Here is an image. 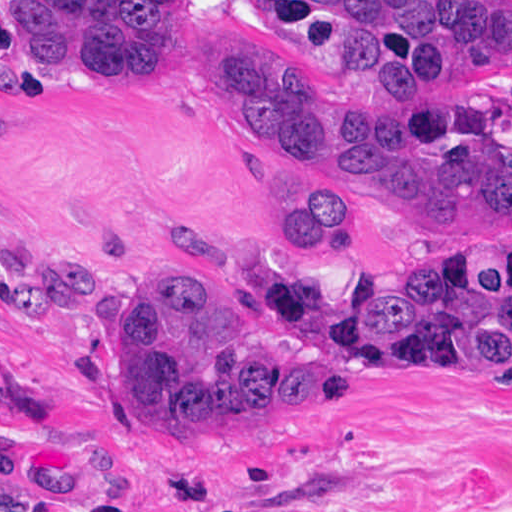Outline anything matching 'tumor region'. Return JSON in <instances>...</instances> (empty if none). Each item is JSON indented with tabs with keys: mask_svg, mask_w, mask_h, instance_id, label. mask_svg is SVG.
Returning a JSON list of instances; mask_svg holds the SVG:
<instances>
[{
	"mask_svg": "<svg viewBox=\"0 0 512 512\" xmlns=\"http://www.w3.org/2000/svg\"><path fill=\"white\" fill-rule=\"evenodd\" d=\"M266 1L347 70V98L284 77L234 24L197 33L188 0H7V67L59 115L125 119L155 82L191 66L254 143L328 184L263 197L264 221L298 249L347 246L334 189L433 226L512 235V89L434 83L512 54V0ZM243 282L261 296L179 260H147L115 340L123 409L185 437L223 407L350 391L352 373L512 380V249L389 266L332 311L317 279L273 250H250ZM0 297L50 330L103 318L98 266L23 261L1 276Z\"/></svg>",
	"mask_w": 512,
	"mask_h": 512,
	"instance_id": "obj_1",
	"label": "tumor region"
}]
</instances>
